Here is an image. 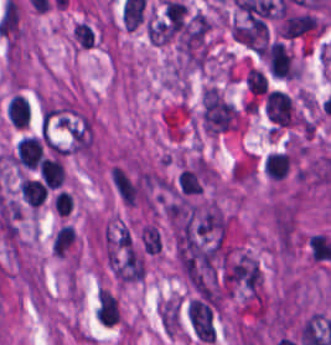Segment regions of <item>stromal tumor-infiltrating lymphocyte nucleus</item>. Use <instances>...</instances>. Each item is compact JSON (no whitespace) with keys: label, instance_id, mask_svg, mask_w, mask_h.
I'll list each match as a JSON object with an SVG mask.
<instances>
[{"label":"stromal tumor-infiltrating lymphocyte nucleus","instance_id":"bc302bb0","mask_svg":"<svg viewBox=\"0 0 331 345\" xmlns=\"http://www.w3.org/2000/svg\"><path fill=\"white\" fill-rule=\"evenodd\" d=\"M119 315L117 298L107 289L99 290L96 303L97 321L105 325H113Z\"/></svg>","mask_w":331,"mask_h":345},{"label":"stromal tumor-infiltrating lymphocyte nucleus","instance_id":"52c7bb5b","mask_svg":"<svg viewBox=\"0 0 331 345\" xmlns=\"http://www.w3.org/2000/svg\"><path fill=\"white\" fill-rule=\"evenodd\" d=\"M65 168L56 157H44L39 166L40 179L49 188L63 184Z\"/></svg>","mask_w":331,"mask_h":345},{"label":"stromal tumor-infiltrating lymphocyte nucleus","instance_id":"3290ff9b","mask_svg":"<svg viewBox=\"0 0 331 345\" xmlns=\"http://www.w3.org/2000/svg\"><path fill=\"white\" fill-rule=\"evenodd\" d=\"M47 188L40 181L23 179L20 181V195L33 207H40L46 198Z\"/></svg>","mask_w":331,"mask_h":345},{"label":"stromal tumor-infiltrating lymphocyte nucleus","instance_id":"abfb95fc","mask_svg":"<svg viewBox=\"0 0 331 345\" xmlns=\"http://www.w3.org/2000/svg\"><path fill=\"white\" fill-rule=\"evenodd\" d=\"M29 105L21 95H14L6 104V117L13 126H26Z\"/></svg>","mask_w":331,"mask_h":345}]
</instances>
